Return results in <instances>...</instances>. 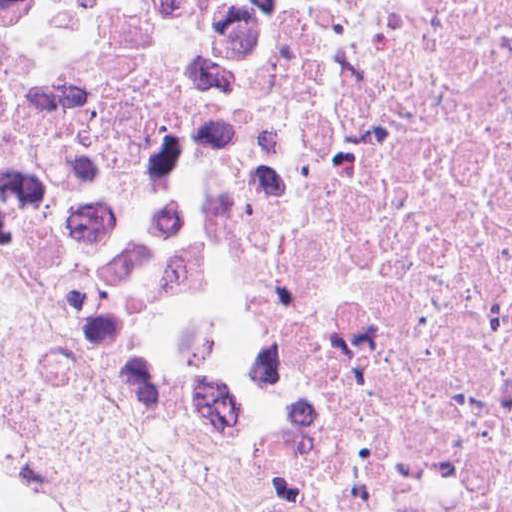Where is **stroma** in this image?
<instances>
[{"mask_svg": "<svg viewBox=\"0 0 512 512\" xmlns=\"http://www.w3.org/2000/svg\"><path fill=\"white\" fill-rule=\"evenodd\" d=\"M0 438L83 512H345L288 445L151 408L2 292Z\"/></svg>", "mask_w": 512, "mask_h": 512, "instance_id": "obj_1", "label": "stroma"}]
</instances>
